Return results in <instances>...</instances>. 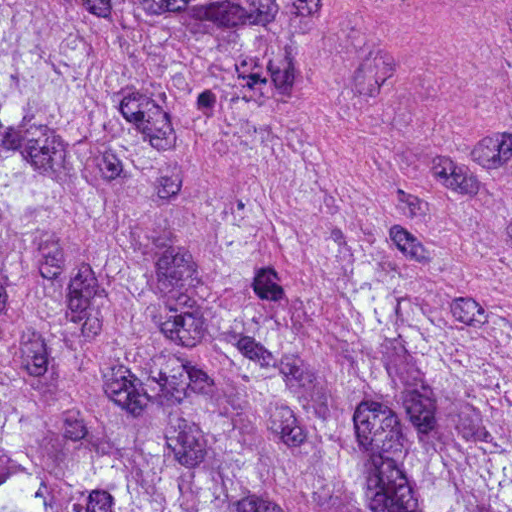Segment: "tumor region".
Wrapping results in <instances>:
<instances>
[{
	"label": "tumor region",
	"mask_w": 512,
	"mask_h": 512,
	"mask_svg": "<svg viewBox=\"0 0 512 512\" xmlns=\"http://www.w3.org/2000/svg\"><path fill=\"white\" fill-rule=\"evenodd\" d=\"M331 0H0V512H512V371L236 180Z\"/></svg>",
	"instance_id": "e687c5a6"
}]
</instances>
